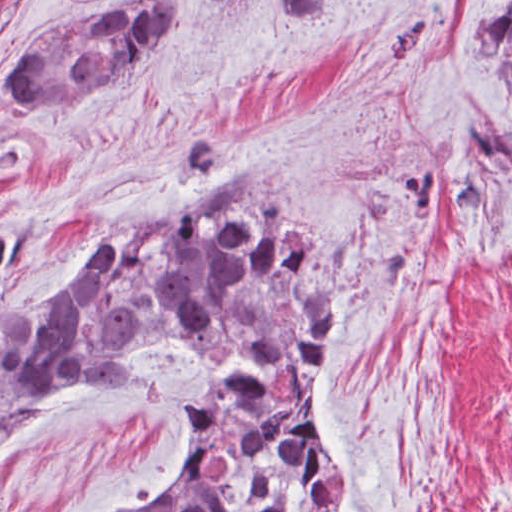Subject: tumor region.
<instances>
[{
	"mask_svg": "<svg viewBox=\"0 0 512 512\" xmlns=\"http://www.w3.org/2000/svg\"><path fill=\"white\" fill-rule=\"evenodd\" d=\"M183 21L184 0L76 11L27 44L8 92L25 106L81 103L153 59ZM469 46L512 106V3ZM19 245L15 222L0 221V285ZM346 250L255 175L111 228L42 310L16 300L0 328V442L86 373L129 385L145 351L189 343L208 364L191 449L174 489L146 512H345L319 404Z\"/></svg>",
	"mask_w": 512,
	"mask_h": 512,
	"instance_id": "tumor-region-1",
	"label": "tumor region"
}]
</instances>
